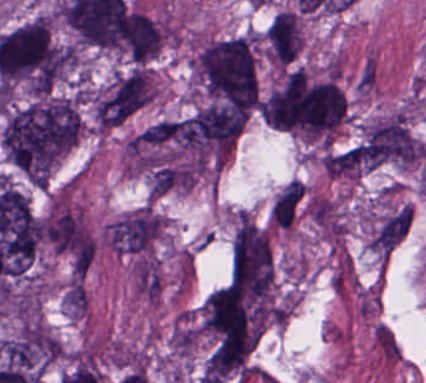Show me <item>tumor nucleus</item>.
Masks as SVG:
<instances>
[{
    "label": "tumor nucleus",
    "instance_id": "obj_7",
    "mask_svg": "<svg viewBox=\"0 0 426 383\" xmlns=\"http://www.w3.org/2000/svg\"><path fill=\"white\" fill-rule=\"evenodd\" d=\"M303 47V31L295 10L277 12L265 31V50L268 58L277 63L297 59Z\"/></svg>",
    "mask_w": 426,
    "mask_h": 383
},
{
    "label": "tumor nucleus",
    "instance_id": "obj_5",
    "mask_svg": "<svg viewBox=\"0 0 426 383\" xmlns=\"http://www.w3.org/2000/svg\"><path fill=\"white\" fill-rule=\"evenodd\" d=\"M163 28L142 9L122 0L115 19L112 47L134 62H144L160 46Z\"/></svg>",
    "mask_w": 426,
    "mask_h": 383
},
{
    "label": "tumor nucleus",
    "instance_id": "obj_4",
    "mask_svg": "<svg viewBox=\"0 0 426 383\" xmlns=\"http://www.w3.org/2000/svg\"><path fill=\"white\" fill-rule=\"evenodd\" d=\"M134 155L178 156L199 152L195 114L158 118L138 129L127 143Z\"/></svg>",
    "mask_w": 426,
    "mask_h": 383
},
{
    "label": "tumor nucleus",
    "instance_id": "obj_2",
    "mask_svg": "<svg viewBox=\"0 0 426 383\" xmlns=\"http://www.w3.org/2000/svg\"><path fill=\"white\" fill-rule=\"evenodd\" d=\"M194 73L211 94L245 106H256L257 80L246 38L209 43L196 57Z\"/></svg>",
    "mask_w": 426,
    "mask_h": 383
},
{
    "label": "tumor nucleus",
    "instance_id": "obj_8",
    "mask_svg": "<svg viewBox=\"0 0 426 383\" xmlns=\"http://www.w3.org/2000/svg\"><path fill=\"white\" fill-rule=\"evenodd\" d=\"M305 195L304 183L289 181L278 194L272 206L271 215L277 227L289 228L299 210Z\"/></svg>",
    "mask_w": 426,
    "mask_h": 383
},
{
    "label": "tumor nucleus",
    "instance_id": "obj_3",
    "mask_svg": "<svg viewBox=\"0 0 426 383\" xmlns=\"http://www.w3.org/2000/svg\"><path fill=\"white\" fill-rule=\"evenodd\" d=\"M200 330L219 342L252 346V298L227 284L215 290L200 310Z\"/></svg>",
    "mask_w": 426,
    "mask_h": 383
},
{
    "label": "tumor nucleus",
    "instance_id": "obj_6",
    "mask_svg": "<svg viewBox=\"0 0 426 383\" xmlns=\"http://www.w3.org/2000/svg\"><path fill=\"white\" fill-rule=\"evenodd\" d=\"M155 94L148 68L116 73L97 100L103 122H118L151 100Z\"/></svg>",
    "mask_w": 426,
    "mask_h": 383
},
{
    "label": "tumor nucleus",
    "instance_id": "obj_1",
    "mask_svg": "<svg viewBox=\"0 0 426 383\" xmlns=\"http://www.w3.org/2000/svg\"><path fill=\"white\" fill-rule=\"evenodd\" d=\"M80 131V116L67 97L39 99L13 110L1 141L11 160L32 180L46 181Z\"/></svg>",
    "mask_w": 426,
    "mask_h": 383
}]
</instances>
